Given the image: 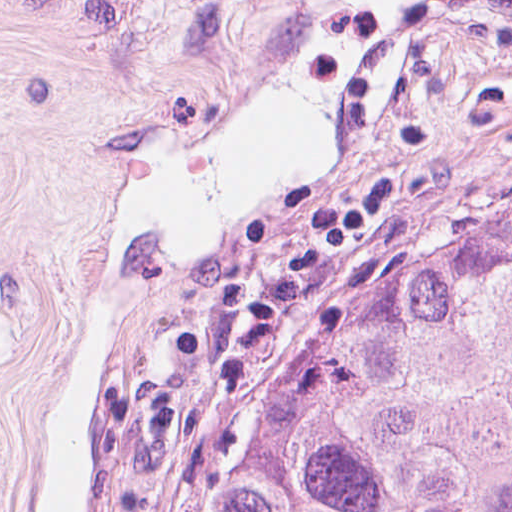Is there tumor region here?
<instances>
[{"label": "tumor region", "instance_id": "1", "mask_svg": "<svg viewBox=\"0 0 512 512\" xmlns=\"http://www.w3.org/2000/svg\"><path fill=\"white\" fill-rule=\"evenodd\" d=\"M136 512H512V177L282 288Z\"/></svg>", "mask_w": 512, "mask_h": 512}]
</instances>
